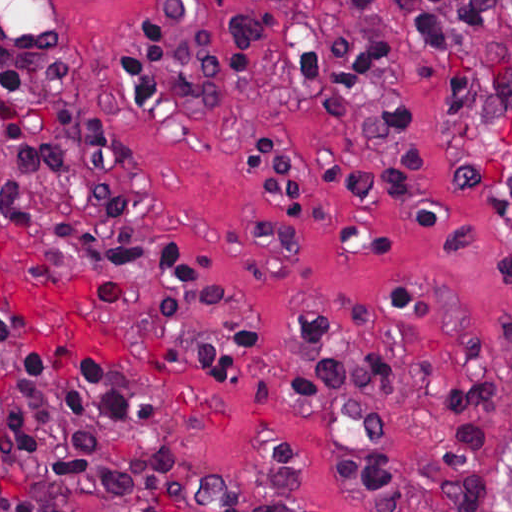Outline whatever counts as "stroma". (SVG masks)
I'll return each mask as SVG.
<instances>
[{
	"instance_id": "obj_1",
	"label": "stroma",
	"mask_w": 512,
	"mask_h": 512,
	"mask_svg": "<svg viewBox=\"0 0 512 512\" xmlns=\"http://www.w3.org/2000/svg\"><path fill=\"white\" fill-rule=\"evenodd\" d=\"M42 1L99 111L122 133L178 241L238 315L250 378L234 401L150 374L96 316L31 267L8 224L0 167V311L29 318L150 396L167 415L169 512H369L342 469L327 400L293 387V320L377 345V423L412 512H512V72L453 122L424 76L408 80L418 173L363 188L333 170L344 105L270 93L271 119L311 196L281 199L246 172L232 97L164 133L126 104L116 67L139 1ZM134 351L181 380L229 389L83 300ZM0 512H11L0 496Z\"/></svg>"
}]
</instances>
